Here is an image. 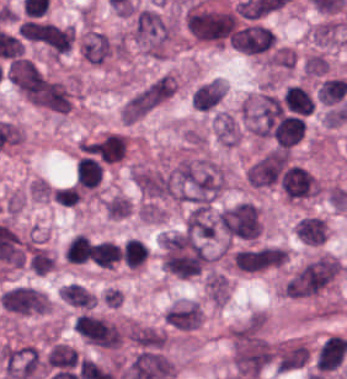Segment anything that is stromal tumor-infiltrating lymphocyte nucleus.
<instances>
[{
  "label": "stromal tumor-infiltrating lymphocyte nucleus",
  "mask_w": 347,
  "mask_h": 379,
  "mask_svg": "<svg viewBox=\"0 0 347 379\" xmlns=\"http://www.w3.org/2000/svg\"><path fill=\"white\" fill-rule=\"evenodd\" d=\"M1 307L18 317L43 315L48 310V296L35 287L18 284L2 291Z\"/></svg>",
  "instance_id": "1"
},
{
  "label": "stromal tumor-infiltrating lymphocyte nucleus",
  "mask_w": 347,
  "mask_h": 379,
  "mask_svg": "<svg viewBox=\"0 0 347 379\" xmlns=\"http://www.w3.org/2000/svg\"><path fill=\"white\" fill-rule=\"evenodd\" d=\"M276 37L272 30L258 24L247 25L231 35V43L238 51L258 54L267 52Z\"/></svg>",
  "instance_id": "2"
},
{
  "label": "stromal tumor-infiltrating lymphocyte nucleus",
  "mask_w": 347,
  "mask_h": 379,
  "mask_svg": "<svg viewBox=\"0 0 347 379\" xmlns=\"http://www.w3.org/2000/svg\"><path fill=\"white\" fill-rule=\"evenodd\" d=\"M285 198L304 200L317 193L316 179L305 168L290 166L280 177Z\"/></svg>",
  "instance_id": "3"
},
{
  "label": "stromal tumor-infiltrating lymphocyte nucleus",
  "mask_w": 347,
  "mask_h": 379,
  "mask_svg": "<svg viewBox=\"0 0 347 379\" xmlns=\"http://www.w3.org/2000/svg\"><path fill=\"white\" fill-rule=\"evenodd\" d=\"M201 317L200 305L191 300H184L173 304L163 320L174 331L191 332L199 326Z\"/></svg>",
  "instance_id": "4"
},
{
  "label": "stromal tumor-infiltrating lymphocyte nucleus",
  "mask_w": 347,
  "mask_h": 379,
  "mask_svg": "<svg viewBox=\"0 0 347 379\" xmlns=\"http://www.w3.org/2000/svg\"><path fill=\"white\" fill-rule=\"evenodd\" d=\"M91 156L103 163H116L125 158L127 139L120 132H107L89 147Z\"/></svg>",
  "instance_id": "5"
},
{
  "label": "stromal tumor-infiltrating lymphocyte nucleus",
  "mask_w": 347,
  "mask_h": 379,
  "mask_svg": "<svg viewBox=\"0 0 347 379\" xmlns=\"http://www.w3.org/2000/svg\"><path fill=\"white\" fill-rule=\"evenodd\" d=\"M296 236L305 244L319 245L326 238V228L322 218L306 216L296 221Z\"/></svg>",
  "instance_id": "6"
},
{
  "label": "stromal tumor-infiltrating lymphocyte nucleus",
  "mask_w": 347,
  "mask_h": 379,
  "mask_svg": "<svg viewBox=\"0 0 347 379\" xmlns=\"http://www.w3.org/2000/svg\"><path fill=\"white\" fill-rule=\"evenodd\" d=\"M206 297L216 306H223L230 295V280L225 273L209 272L204 279Z\"/></svg>",
  "instance_id": "7"
},
{
  "label": "stromal tumor-infiltrating lymphocyte nucleus",
  "mask_w": 347,
  "mask_h": 379,
  "mask_svg": "<svg viewBox=\"0 0 347 379\" xmlns=\"http://www.w3.org/2000/svg\"><path fill=\"white\" fill-rule=\"evenodd\" d=\"M148 254L146 242L129 237L120 251V261L126 269H137L143 266Z\"/></svg>",
  "instance_id": "8"
},
{
  "label": "stromal tumor-infiltrating lymphocyte nucleus",
  "mask_w": 347,
  "mask_h": 379,
  "mask_svg": "<svg viewBox=\"0 0 347 379\" xmlns=\"http://www.w3.org/2000/svg\"><path fill=\"white\" fill-rule=\"evenodd\" d=\"M285 106L291 113L312 114L313 102L306 89L297 84H290L283 95Z\"/></svg>",
  "instance_id": "9"
},
{
  "label": "stromal tumor-infiltrating lymphocyte nucleus",
  "mask_w": 347,
  "mask_h": 379,
  "mask_svg": "<svg viewBox=\"0 0 347 379\" xmlns=\"http://www.w3.org/2000/svg\"><path fill=\"white\" fill-rule=\"evenodd\" d=\"M347 93V81L341 78H327L317 88V99L324 105L341 101Z\"/></svg>",
  "instance_id": "10"
},
{
  "label": "stromal tumor-infiltrating lymphocyte nucleus",
  "mask_w": 347,
  "mask_h": 379,
  "mask_svg": "<svg viewBox=\"0 0 347 379\" xmlns=\"http://www.w3.org/2000/svg\"><path fill=\"white\" fill-rule=\"evenodd\" d=\"M59 295L73 306L90 310L95 304L94 294L84 285L77 283L66 284L60 290Z\"/></svg>",
  "instance_id": "11"
},
{
  "label": "stromal tumor-infiltrating lymphocyte nucleus",
  "mask_w": 347,
  "mask_h": 379,
  "mask_svg": "<svg viewBox=\"0 0 347 379\" xmlns=\"http://www.w3.org/2000/svg\"><path fill=\"white\" fill-rule=\"evenodd\" d=\"M93 246L89 237L77 235L66 249L65 257L70 264H84L92 260Z\"/></svg>",
  "instance_id": "12"
},
{
  "label": "stromal tumor-infiltrating lymphocyte nucleus",
  "mask_w": 347,
  "mask_h": 379,
  "mask_svg": "<svg viewBox=\"0 0 347 379\" xmlns=\"http://www.w3.org/2000/svg\"><path fill=\"white\" fill-rule=\"evenodd\" d=\"M56 201L63 206H74L77 202L69 188H60L55 193Z\"/></svg>",
  "instance_id": "13"
}]
</instances>
